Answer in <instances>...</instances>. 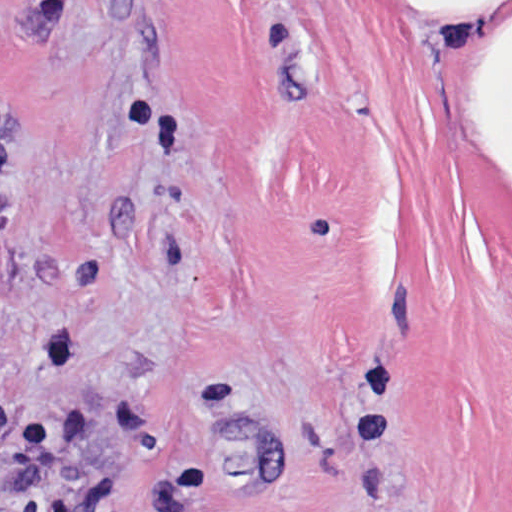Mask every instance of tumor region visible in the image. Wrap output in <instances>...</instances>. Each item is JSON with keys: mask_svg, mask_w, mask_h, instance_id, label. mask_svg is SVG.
Returning a JSON list of instances; mask_svg holds the SVG:
<instances>
[{"mask_svg": "<svg viewBox=\"0 0 512 512\" xmlns=\"http://www.w3.org/2000/svg\"><path fill=\"white\" fill-rule=\"evenodd\" d=\"M11 309V337L17 312V296L0 281V328L5 326Z\"/></svg>", "mask_w": 512, "mask_h": 512, "instance_id": "tumor-region-1", "label": "tumor region"}]
</instances>
